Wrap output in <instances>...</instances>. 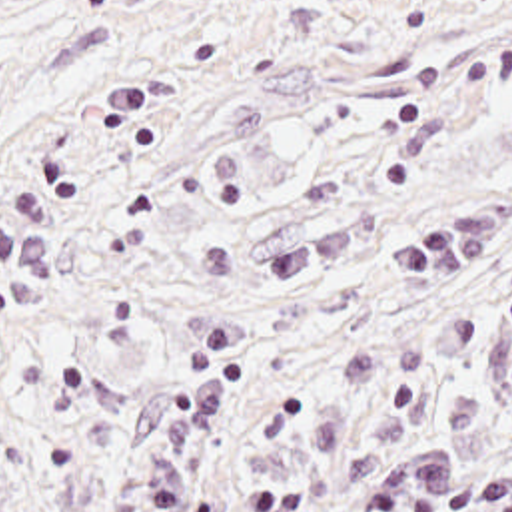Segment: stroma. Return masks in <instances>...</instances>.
<instances>
[{"mask_svg":"<svg viewBox=\"0 0 512 512\" xmlns=\"http://www.w3.org/2000/svg\"><path fill=\"white\" fill-rule=\"evenodd\" d=\"M0 512H512V0H0Z\"/></svg>","mask_w":512,"mask_h":512,"instance_id":"1","label":"stroma"}]
</instances>
